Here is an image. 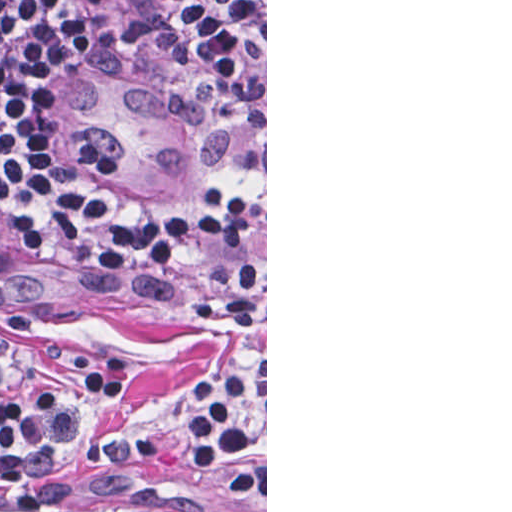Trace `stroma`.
<instances>
[{"instance_id": "obj_1", "label": "stroma", "mask_w": 512, "mask_h": 512, "mask_svg": "<svg viewBox=\"0 0 512 512\" xmlns=\"http://www.w3.org/2000/svg\"><path fill=\"white\" fill-rule=\"evenodd\" d=\"M253 1L266 10L258 136L233 169L185 196L203 193L187 202H154L82 168L57 142L51 130L57 57L49 3L32 0L33 128L82 185L123 209H149L193 223L200 196L214 188L249 190L266 210L265 300L254 329L242 333L205 318L196 303L198 287L187 275L139 253L79 249L0 232V361L13 375L42 378L66 366L86 344L114 350L135 372L131 417L63 462L58 506L42 512H218L208 485L184 464L178 400L232 358L246 360L266 383V489L253 493L249 512H267V0Z\"/></svg>"}]
</instances>
